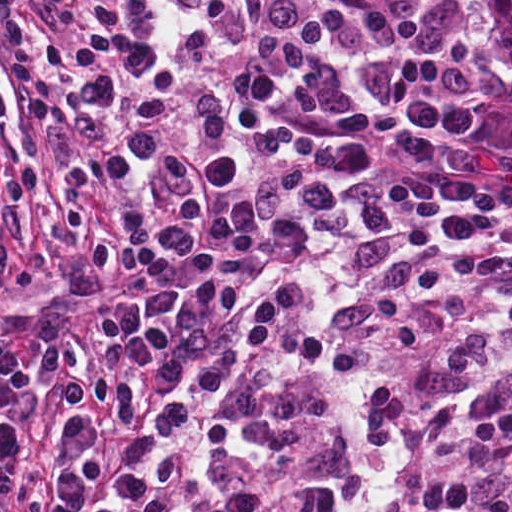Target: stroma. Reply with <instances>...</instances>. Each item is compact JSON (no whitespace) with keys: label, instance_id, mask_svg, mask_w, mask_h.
Returning <instances> with one entry per match:
<instances>
[{"label":"stroma","instance_id":"1","mask_svg":"<svg viewBox=\"0 0 512 512\" xmlns=\"http://www.w3.org/2000/svg\"><path fill=\"white\" fill-rule=\"evenodd\" d=\"M451 5L467 29L490 71L473 90L470 104L487 122L512 109V57L495 27L487 0H433ZM0 81L12 86L15 111L9 128L17 136V119L30 99L40 91L24 74L21 64L0 34ZM508 90V91H507ZM506 92L501 106L497 103ZM67 158L52 128L42 139L41 176L37 185L18 196V209L26 224L20 249L24 257L50 255L51 268L40 275L35 287L0 276V321L16 331L33 352L54 332L101 311L116 301L138 294H125L111 285L80 253L73 219L64 209L54 179ZM0 147V177L5 164ZM359 218L357 210L335 199L313 208L300 222L274 243L249 255L227 278L230 294L244 301L248 346L244 369L236 388L219 415L214 429L188 461L184 473L159 512L170 504L178 489L211 466L231 435L250 394L257 370V323L263 294L282 264L298 244L303 232L322 222Z\"/></svg>","mask_w":512,"mask_h":512}]
</instances>
